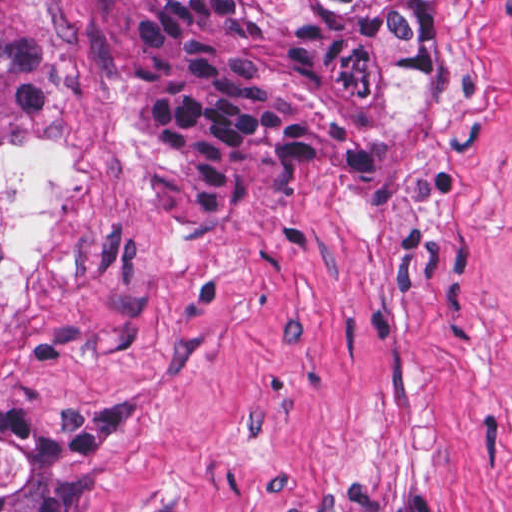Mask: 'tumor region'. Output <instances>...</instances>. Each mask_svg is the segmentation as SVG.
Returning <instances> with one entry per match:
<instances>
[{
	"instance_id": "tumor-region-1",
	"label": "tumor region",
	"mask_w": 512,
	"mask_h": 512,
	"mask_svg": "<svg viewBox=\"0 0 512 512\" xmlns=\"http://www.w3.org/2000/svg\"><path fill=\"white\" fill-rule=\"evenodd\" d=\"M66 32L46 0H0V139L51 125ZM451 108L449 0H140L134 15L138 209L150 231L203 233L276 179L332 196L407 183ZM4 226L0 216V238ZM30 432L0 397V445ZM69 438L36 441L0 512H85Z\"/></svg>"
}]
</instances>
